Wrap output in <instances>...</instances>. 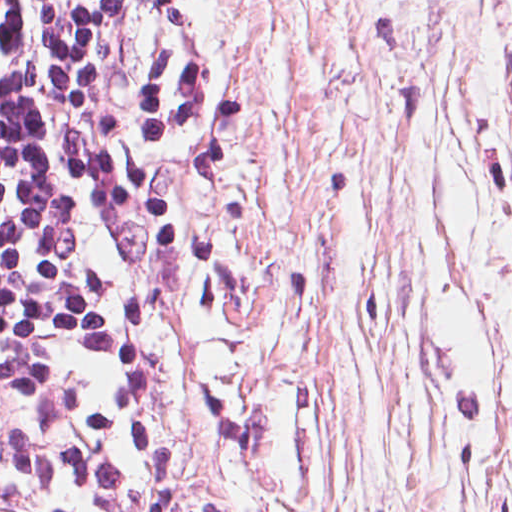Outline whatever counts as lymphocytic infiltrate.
<instances>
[{
    "label": "lymphocytic infiltrate",
    "mask_w": 512,
    "mask_h": 512,
    "mask_svg": "<svg viewBox=\"0 0 512 512\" xmlns=\"http://www.w3.org/2000/svg\"><path fill=\"white\" fill-rule=\"evenodd\" d=\"M145 0H0V512H85L148 356L134 239L84 181L130 140Z\"/></svg>",
    "instance_id": "lymphocytic-infiltrate-1"
}]
</instances>
